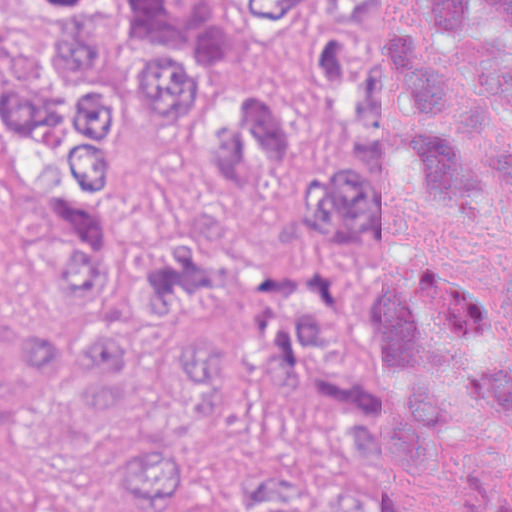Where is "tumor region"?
Returning a JSON list of instances; mask_svg holds the SVG:
<instances>
[{
  "mask_svg": "<svg viewBox=\"0 0 512 512\" xmlns=\"http://www.w3.org/2000/svg\"><path fill=\"white\" fill-rule=\"evenodd\" d=\"M0 512H512V0H0Z\"/></svg>",
  "mask_w": 512,
  "mask_h": 512,
  "instance_id": "obj_1",
  "label": "tumor region"
}]
</instances>
